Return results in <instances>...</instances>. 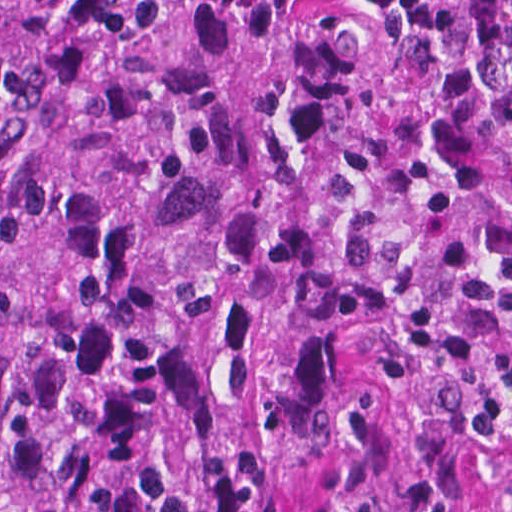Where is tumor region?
<instances>
[{
    "label": "tumor region",
    "instance_id": "obj_1",
    "mask_svg": "<svg viewBox=\"0 0 512 512\" xmlns=\"http://www.w3.org/2000/svg\"><path fill=\"white\" fill-rule=\"evenodd\" d=\"M506 485L512 0H0V512Z\"/></svg>",
    "mask_w": 512,
    "mask_h": 512
}]
</instances>
